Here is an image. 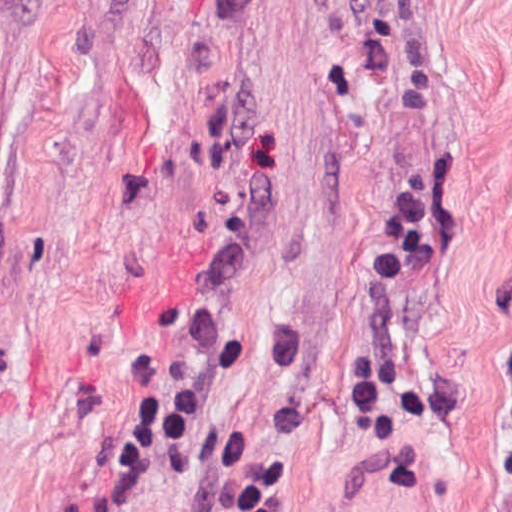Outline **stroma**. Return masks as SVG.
<instances>
[{
    "instance_id": "obj_1",
    "label": "stroma",
    "mask_w": 512,
    "mask_h": 512,
    "mask_svg": "<svg viewBox=\"0 0 512 512\" xmlns=\"http://www.w3.org/2000/svg\"><path fill=\"white\" fill-rule=\"evenodd\" d=\"M403 187L442 235L336 445ZM154 366L293 512H512V0H0V512H69Z\"/></svg>"
}]
</instances>
